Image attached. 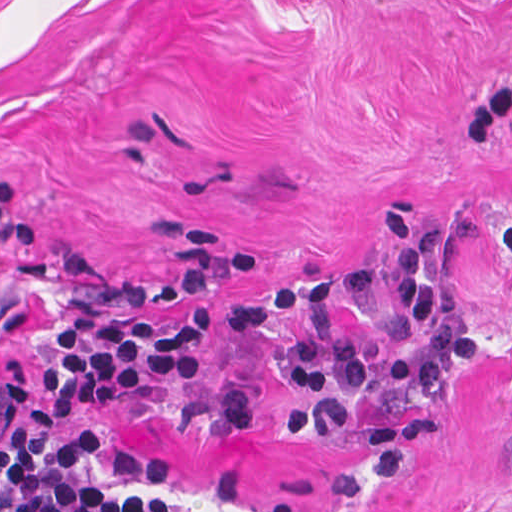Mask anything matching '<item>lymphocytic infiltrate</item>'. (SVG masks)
Wrapping results in <instances>:
<instances>
[{"label":"lymphocytic infiltrate","mask_w":512,"mask_h":512,"mask_svg":"<svg viewBox=\"0 0 512 512\" xmlns=\"http://www.w3.org/2000/svg\"><path fill=\"white\" fill-rule=\"evenodd\" d=\"M383 231L395 247L394 264L357 271L353 286L405 303L423 324L418 341L350 339L344 291L331 276L293 277L229 313L232 329L275 312L305 316V325L287 335L275 367L290 391L285 423L297 439H315L335 421L341 393L432 389L459 351V318L440 299L435 267L445 228L395 211ZM57 322L62 352L55 374L1 428V512H195L158 487L100 482L91 475L101 442L94 421L61 429L72 413L202 371L204 345L222 332L224 309L213 301L174 319L70 309Z\"/></svg>","instance_id":"f902f5d3"}]
</instances>
